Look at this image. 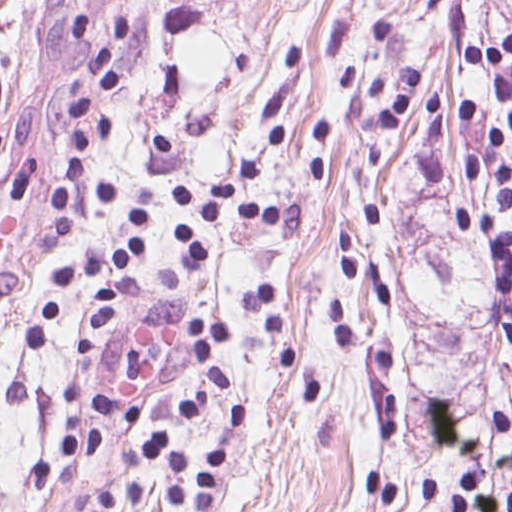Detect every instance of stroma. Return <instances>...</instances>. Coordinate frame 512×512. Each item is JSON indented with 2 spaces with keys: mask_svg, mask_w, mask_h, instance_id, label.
<instances>
[{
  "mask_svg": "<svg viewBox=\"0 0 512 512\" xmlns=\"http://www.w3.org/2000/svg\"><path fill=\"white\" fill-rule=\"evenodd\" d=\"M123 20L122 85L84 84L87 116L113 119L92 149L112 199L81 190L56 242L66 97ZM511 33L499 0H0V512H70L119 481L193 512L167 503L149 433L190 461L191 491L227 441L211 512H435L422 476L448 500L461 471L505 491L512 291L454 211L498 199L465 178L488 135L467 110L506 118L462 48ZM272 131L249 199L297 204L305 235L212 224L191 255L179 185L213 197ZM141 207L140 261L102 273L120 294L91 357L86 281L32 345L60 266L128 250ZM198 313L227 330L232 390L201 370Z\"/></svg>",
  "mask_w": 512,
  "mask_h": 512,
  "instance_id": "1",
  "label": "stroma"
}]
</instances>
